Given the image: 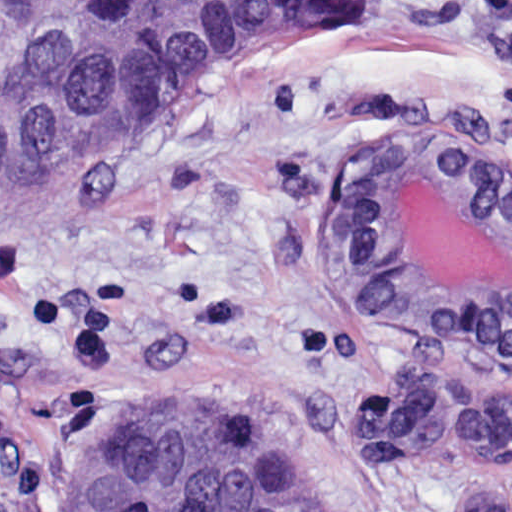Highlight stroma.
Masks as SVG:
<instances>
[{
	"instance_id": "1",
	"label": "stroma",
	"mask_w": 512,
	"mask_h": 512,
	"mask_svg": "<svg viewBox=\"0 0 512 512\" xmlns=\"http://www.w3.org/2000/svg\"><path fill=\"white\" fill-rule=\"evenodd\" d=\"M156 126L0 205V512H62L134 396H203L287 443L323 512H512V458L380 460L328 416L428 387L512 403V358L384 327L345 223L385 137H473L512 175V67L461 0H365Z\"/></svg>"
}]
</instances>
